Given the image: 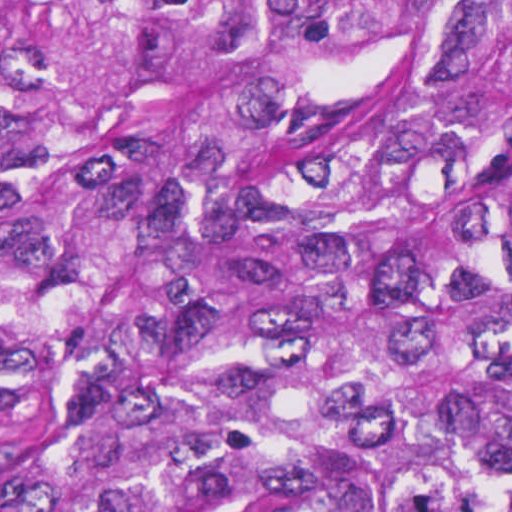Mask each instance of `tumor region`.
I'll return each mask as SVG.
<instances>
[{"label":"tumor region","instance_id":"1","mask_svg":"<svg viewBox=\"0 0 512 512\" xmlns=\"http://www.w3.org/2000/svg\"><path fill=\"white\" fill-rule=\"evenodd\" d=\"M0 512H512V0H0Z\"/></svg>","mask_w":512,"mask_h":512}]
</instances>
